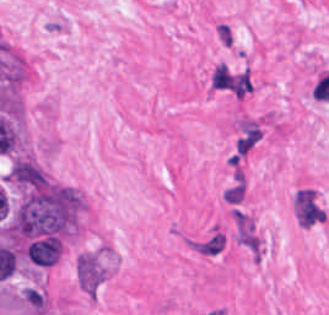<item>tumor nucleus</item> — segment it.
Wrapping results in <instances>:
<instances>
[{
  "mask_svg": "<svg viewBox=\"0 0 329 315\" xmlns=\"http://www.w3.org/2000/svg\"><path fill=\"white\" fill-rule=\"evenodd\" d=\"M9 178L25 188L42 187L48 182L41 168L31 159L17 156L10 169Z\"/></svg>",
  "mask_w": 329,
  "mask_h": 315,
  "instance_id": "2f306a5c",
  "label": "tumor nucleus"
},
{
  "mask_svg": "<svg viewBox=\"0 0 329 315\" xmlns=\"http://www.w3.org/2000/svg\"><path fill=\"white\" fill-rule=\"evenodd\" d=\"M60 239L41 237L27 245L26 253L31 262L38 265H53L60 254Z\"/></svg>",
  "mask_w": 329,
  "mask_h": 315,
  "instance_id": "8643909e",
  "label": "tumor nucleus"
}]
</instances>
